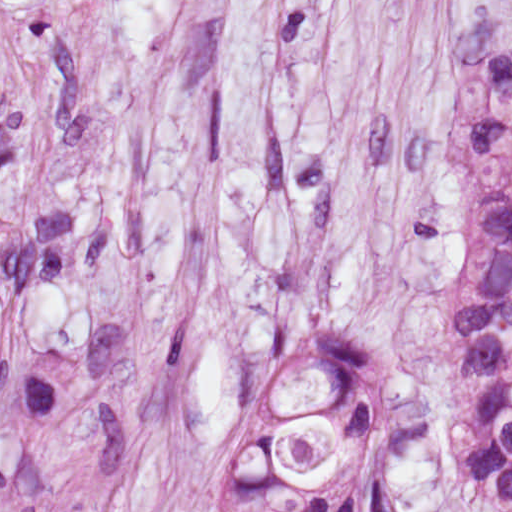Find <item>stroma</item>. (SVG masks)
<instances>
[{
    "mask_svg": "<svg viewBox=\"0 0 512 512\" xmlns=\"http://www.w3.org/2000/svg\"><path fill=\"white\" fill-rule=\"evenodd\" d=\"M512 0H0V512H213L289 351L404 415L363 512H505L449 435Z\"/></svg>",
    "mask_w": 512,
    "mask_h": 512,
    "instance_id": "1",
    "label": "stroma"
}]
</instances>
